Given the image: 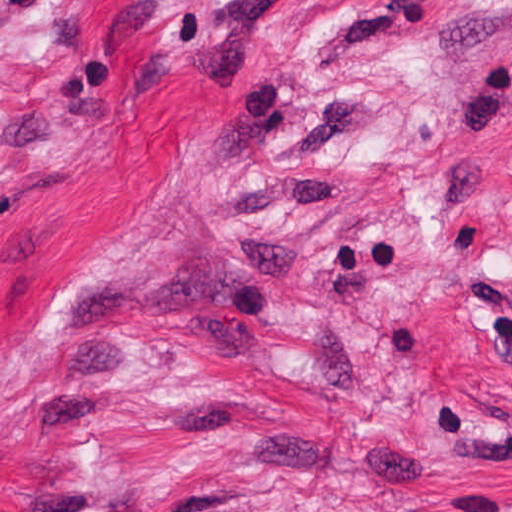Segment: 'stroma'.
Segmentation results:
<instances>
[{"instance_id": "35a3bbf8", "label": "stroma", "mask_w": 512, "mask_h": 512, "mask_svg": "<svg viewBox=\"0 0 512 512\" xmlns=\"http://www.w3.org/2000/svg\"><path fill=\"white\" fill-rule=\"evenodd\" d=\"M0 512H512V0H0Z\"/></svg>"}]
</instances>
